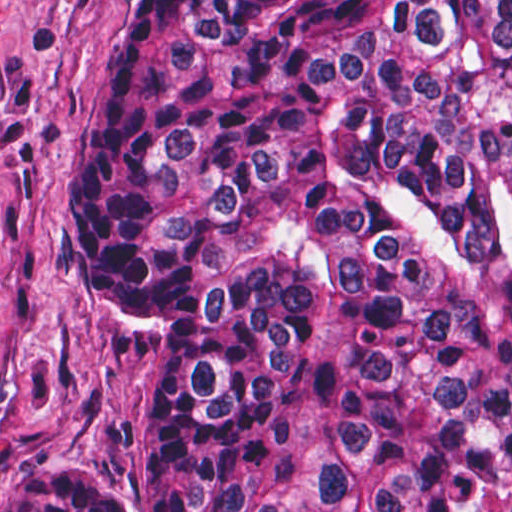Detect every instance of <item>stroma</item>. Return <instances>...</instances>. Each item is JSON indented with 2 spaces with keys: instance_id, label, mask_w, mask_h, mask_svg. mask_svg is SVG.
<instances>
[{
  "instance_id": "obj_1",
  "label": "stroma",
  "mask_w": 512,
  "mask_h": 512,
  "mask_svg": "<svg viewBox=\"0 0 512 512\" xmlns=\"http://www.w3.org/2000/svg\"><path fill=\"white\" fill-rule=\"evenodd\" d=\"M133 0H0L1 488L76 470L135 512L151 358L83 301L65 250L81 128ZM474 512H512V465Z\"/></svg>"
}]
</instances>
